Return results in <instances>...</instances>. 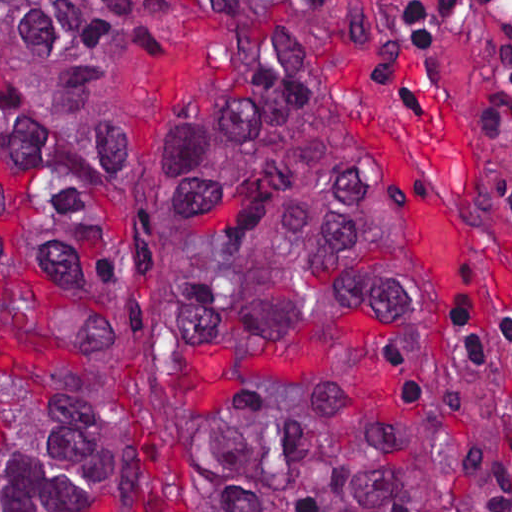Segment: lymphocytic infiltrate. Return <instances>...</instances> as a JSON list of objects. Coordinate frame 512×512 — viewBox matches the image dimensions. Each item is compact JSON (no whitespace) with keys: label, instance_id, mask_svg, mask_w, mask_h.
<instances>
[{"label":"lymphocytic infiltrate","instance_id":"1","mask_svg":"<svg viewBox=\"0 0 512 512\" xmlns=\"http://www.w3.org/2000/svg\"><path fill=\"white\" fill-rule=\"evenodd\" d=\"M414 15L488 105L512 161V1H414ZM508 390V486L512 494V311L495 317Z\"/></svg>","mask_w":512,"mask_h":512}]
</instances>
